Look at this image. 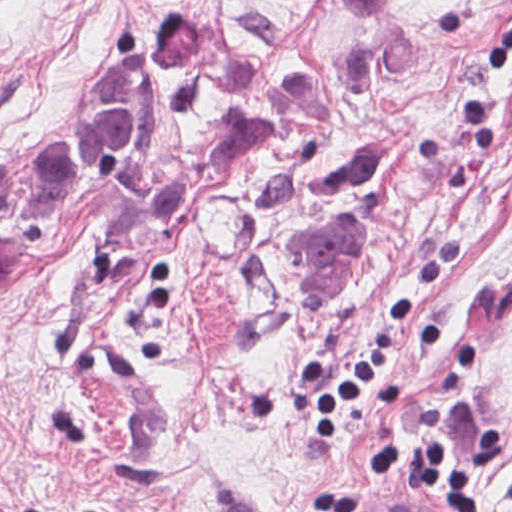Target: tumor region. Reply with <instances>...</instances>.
Instances as JSON below:
<instances>
[{
  "mask_svg": "<svg viewBox=\"0 0 512 512\" xmlns=\"http://www.w3.org/2000/svg\"><path fill=\"white\" fill-rule=\"evenodd\" d=\"M320 19L344 27H380L403 0H299ZM215 42L207 10L176 5L146 27L132 49V70L148 88H183L198 77Z\"/></svg>",
  "mask_w": 512,
  "mask_h": 512,
  "instance_id": "obj_1",
  "label": "tumor region"
}]
</instances>
